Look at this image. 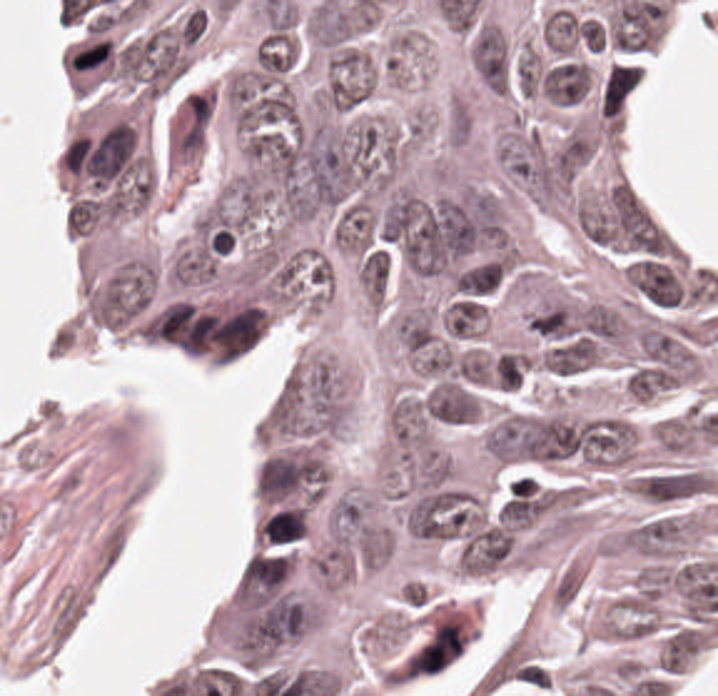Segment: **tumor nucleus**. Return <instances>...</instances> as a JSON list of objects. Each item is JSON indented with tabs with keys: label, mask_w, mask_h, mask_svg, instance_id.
Here are the masks:
<instances>
[{
	"label": "tumor nucleus",
	"mask_w": 718,
	"mask_h": 696,
	"mask_svg": "<svg viewBox=\"0 0 718 696\" xmlns=\"http://www.w3.org/2000/svg\"><path fill=\"white\" fill-rule=\"evenodd\" d=\"M352 419L350 368L309 348L275 391L259 427L262 448L330 441Z\"/></svg>",
	"instance_id": "obj_1"
},
{
	"label": "tumor nucleus",
	"mask_w": 718,
	"mask_h": 696,
	"mask_svg": "<svg viewBox=\"0 0 718 696\" xmlns=\"http://www.w3.org/2000/svg\"><path fill=\"white\" fill-rule=\"evenodd\" d=\"M567 415L559 410H511L481 435V449L505 460L569 456Z\"/></svg>",
	"instance_id": "obj_2"
}]
</instances>
